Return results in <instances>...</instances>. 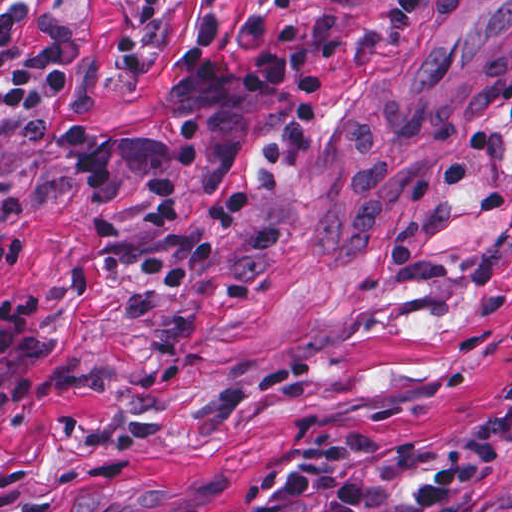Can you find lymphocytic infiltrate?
<instances>
[{
  "label": "lymphocytic infiltrate",
  "mask_w": 512,
  "mask_h": 512,
  "mask_svg": "<svg viewBox=\"0 0 512 512\" xmlns=\"http://www.w3.org/2000/svg\"><path fill=\"white\" fill-rule=\"evenodd\" d=\"M301 0H275V18L251 17L243 36L244 58L257 60L268 38L279 48L252 74L242 77L219 53L224 18L215 11L198 21L184 64L204 90L255 96L272 124L262 133L259 152L267 168H286L320 114L326 87L321 68L340 57L341 20L304 18ZM420 0H393L385 13L389 30H408ZM69 85L61 62H48L41 74L12 78L2 95L9 109L26 121L49 128L91 184H116V161L107 133L94 122L64 113L59 101ZM151 225L171 235L166 246L146 255L140 270L160 291H182L215 261L247 204L245 189L226 199L211 232L197 238L186 222V196L172 177L149 179ZM49 294H0V354L16 353L17 365L0 383V410L27 405L38 389L39 364L52 348L45 324ZM499 431L490 428L463 443L445 464L428 472L410 494H394L368 478L356 457L353 436L315 444L274 476L276 509L298 505L308 512H512V485L493 492H471L492 459ZM187 512H196L194 510Z\"/></svg>",
  "instance_id": "obj_1"
}]
</instances>
